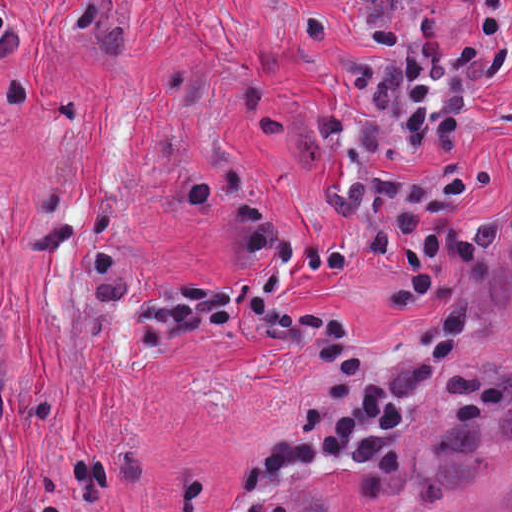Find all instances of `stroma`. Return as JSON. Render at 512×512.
<instances>
[{"mask_svg": "<svg viewBox=\"0 0 512 512\" xmlns=\"http://www.w3.org/2000/svg\"><path fill=\"white\" fill-rule=\"evenodd\" d=\"M0 50V512H512V87L462 138L478 260L399 308L393 258L280 296L404 365L458 302L438 398L384 461L245 470L326 369L293 347L177 331L129 363L110 302L230 291L335 210L331 82L370 30L351 0H10Z\"/></svg>", "mask_w": 512, "mask_h": 512, "instance_id": "35a3bbf8", "label": "stroma"}]
</instances>
